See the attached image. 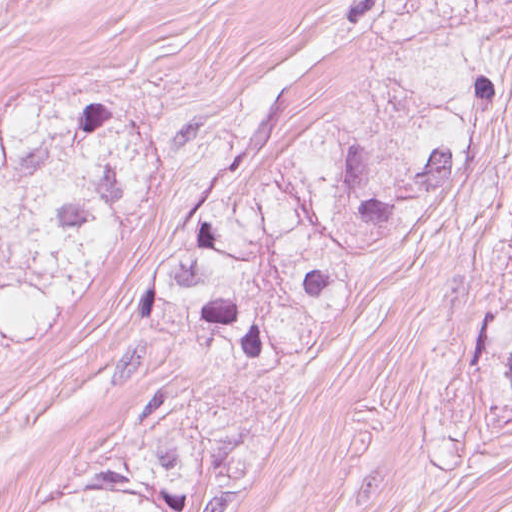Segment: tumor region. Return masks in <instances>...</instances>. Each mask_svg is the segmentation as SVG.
Wrapping results in <instances>:
<instances>
[{
    "label": "tumor region",
    "instance_id": "1",
    "mask_svg": "<svg viewBox=\"0 0 512 512\" xmlns=\"http://www.w3.org/2000/svg\"><path fill=\"white\" fill-rule=\"evenodd\" d=\"M25 460L0 453V502L14 490ZM29 512H180L79 478L39 500Z\"/></svg>",
    "mask_w": 512,
    "mask_h": 512
}]
</instances>
